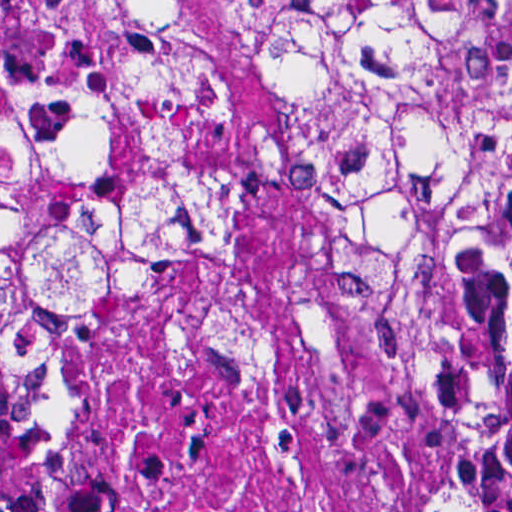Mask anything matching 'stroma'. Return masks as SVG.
Listing matches in <instances>:
<instances>
[{
    "instance_id": "obj_1",
    "label": "stroma",
    "mask_w": 512,
    "mask_h": 512,
    "mask_svg": "<svg viewBox=\"0 0 512 512\" xmlns=\"http://www.w3.org/2000/svg\"><path fill=\"white\" fill-rule=\"evenodd\" d=\"M186 46L190 91L208 122L262 128L300 101L298 76L258 0H161Z\"/></svg>"
}]
</instances>
